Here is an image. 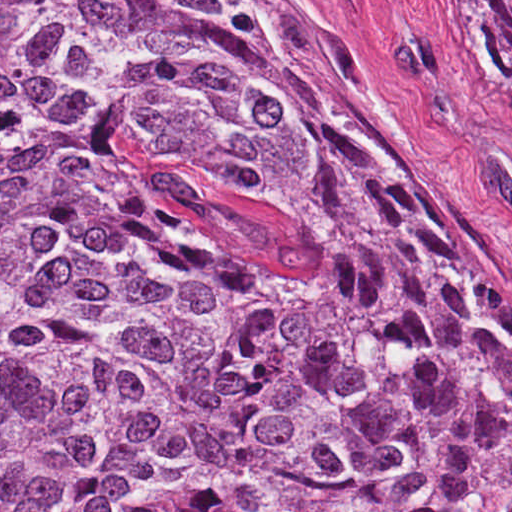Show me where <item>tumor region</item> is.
<instances>
[{
	"instance_id": "1",
	"label": "tumor region",
	"mask_w": 512,
	"mask_h": 512,
	"mask_svg": "<svg viewBox=\"0 0 512 512\" xmlns=\"http://www.w3.org/2000/svg\"><path fill=\"white\" fill-rule=\"evenodd\" d=\"M0 512H512L511 308L295 1H0Z\"/></svg>"
}]
</instances>
